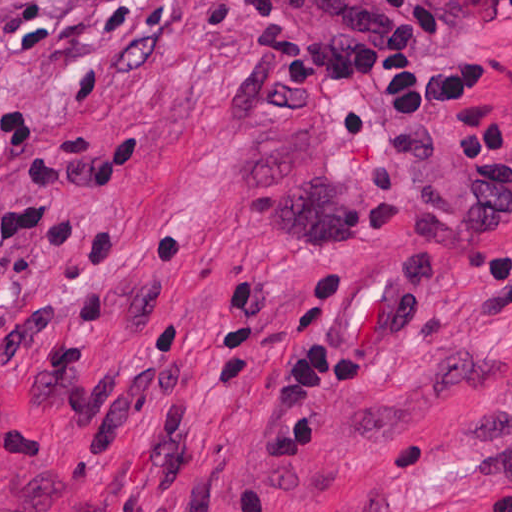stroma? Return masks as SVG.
Returning <instances> with one entry per match:
<instances>
[{"label": "stroma", "instance_id": "obj_1", "mask_svg": "<svg viewBox=\"0 0 512 512\" xmlns=\"http://www.w3.org/2000/svg\"><path fill=\"white\" fill-rule=\"evenodd\" d=\"M512 162V0H442ZM240 0H0V512H512V181L385 90L353 138ZM338 263L331 397L299 462L266 408L285 307ZM351 363L355 359H349Z\"/></svg>", "mask_w": 512, "mask_h": 512}]
</instances>
